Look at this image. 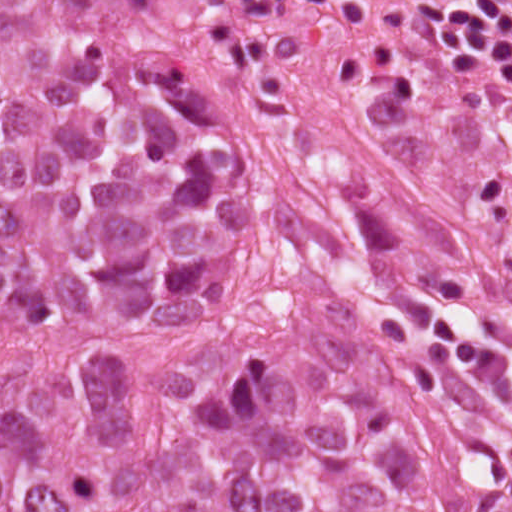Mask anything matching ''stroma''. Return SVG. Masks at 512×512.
Returning <instances> with one entry per match:
<instances>
[{
	"label": "stroma",
	"mask_w": 512,
	"mask_h": 512,
	"mask_svg": "<svg viewBox=\"0 0 512 512\" xmlns=\"http://www.w3.org/2000/svg\"><path fill=\"white\" fill-rule=\"evenodd\" d=\"M178 2L218 66L224 142L254 176L360 202L481 345L512 332V72L427 33L414 0H358L326 23Z\"/></svg>",
	"instance_id": "stroma-1"
}]
</instances>
